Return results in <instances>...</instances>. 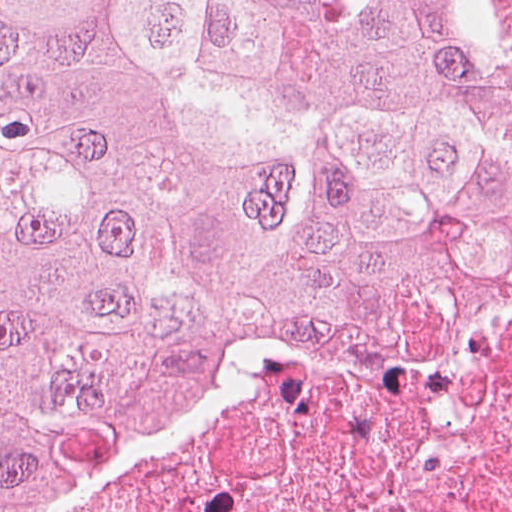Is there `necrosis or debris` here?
<instances>
[{
    "instance_id": "1",
    "label": "necrosis or debris",
    "mask_w": 512,
    "mask_h": 512,
    "mask_svg": "<svg viewBox=\"0 0 512 512\" xmlns=\"http://www.w3.org/2000/svg\"><path fill=\"white\" fill-rule=\"evenodd\" d=\"M85 512H512V294L275 364Z\"/></svg>"
}]
</instances>
